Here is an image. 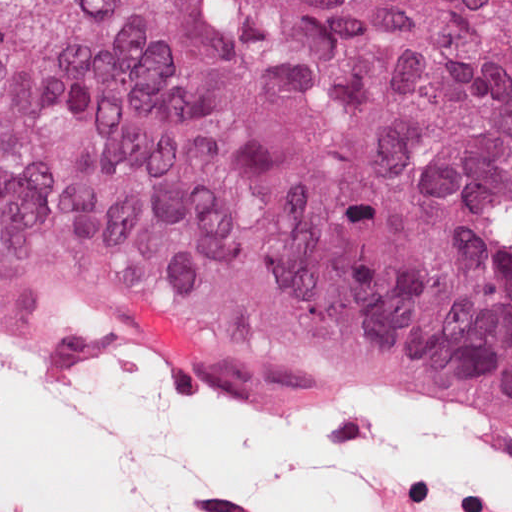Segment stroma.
Masks as SVG:
<instances>
[{"label":"stroma","mask_w":512,"mask_h":512,"mask_svg":"<svg viewBox=\"0 0 512 512\" xmlns=\"http://www.w3.org/2000/svg\"><path fill=\"white\" fill-rule=\"evenodd\" d=\"M100 305L111 306L123 309L131 317L127 311H132L144 315L153 320L168 323L169 325L192 335L209 353L210 357L203 362H189L182 358L178 353L168 348H164L174 358L197 368L211 371L221 375H250L267 371L291 373L299 375L309 374L297 369L273 363L251 354L242 352L238 349L222 346L207 340L201 334L181 325L180 323L169 318L159 309L144 303L104 299V298H59L53 300H13L0 298V306L4 309H82L95 307ZM455 417V416H453ZM482 431L492 435L500 436L504 439L512 441V429L479 424L464 418L456 417Z\"/></svg>","instance_id":"stroma-1"}]
</instances>
